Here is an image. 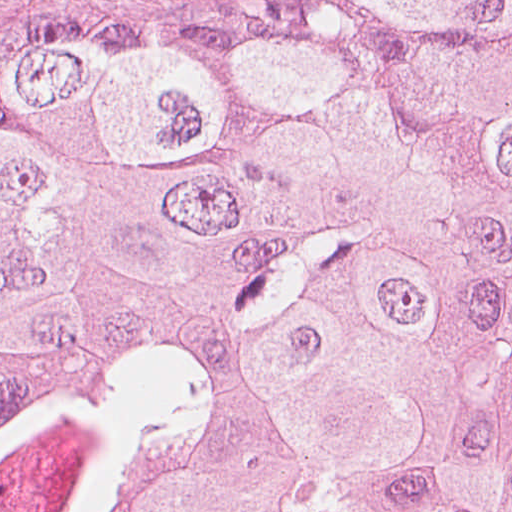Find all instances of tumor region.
<instances>
[{"instance_id": "e687c5a6", "label": "tumor region", "mask_w": 512, "mask_h": 512, "mask_svg": "<svg viewBox=\"0 0 512 512\" xmlns=\"http://www.w3.org/2000/svg\"><path fill=\"white\" fill-rule=\"evenodd\" d=\"M0 512H512V0L0 81Z\"/></svg>"}]
</instances>
